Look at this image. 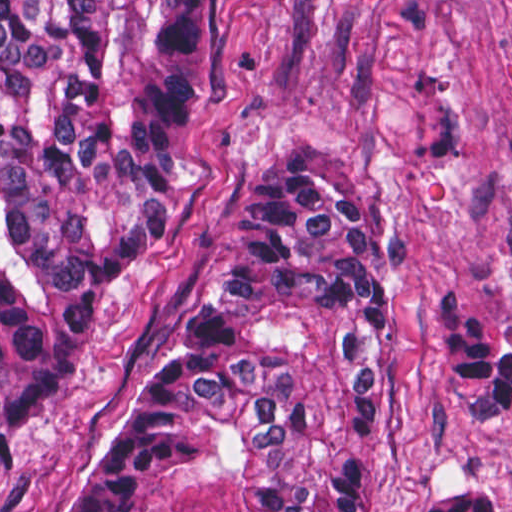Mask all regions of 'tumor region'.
Instances as JSON below:
<instances>
[{"mask_svg": "<svg viewBox=\"0 0 512 512\" xmlns=\"http://www.w3.org/2000/svg\"><path fill=\"white\" fill-rule=\"evenodd\" d=\"M195 0H0V464L63 399L112 282L183 214ZM390 276L364 182L280 145L164 368L69 512H360ZM487 422L512 344L444 311Z\"/></svg>", "mask_w": 512, "mask_h": 512, "instance_id": "obj_1", "label": "tumor region"}]
</instances>
